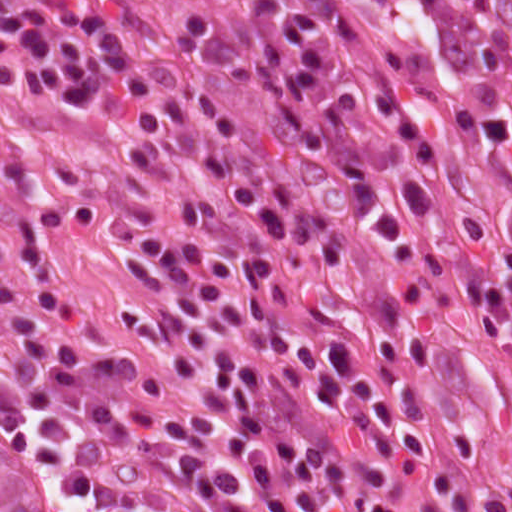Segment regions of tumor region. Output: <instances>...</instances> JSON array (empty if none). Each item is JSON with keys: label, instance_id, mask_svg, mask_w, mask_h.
<instances>
[{"label": "tumor region", "instance_id": "obj_1", "mask_svg": "<svg viewBox=\"0 0 512 512\" xmlns=\"http://www.w3.org/2000/svg\"><path fill=\"white\" fill-rule=\"evenodd\" d=\"M354 66L437 128L475 219L512 253V0H296Z\"/></svg>", "mask_w": 512, "mask_h": 512}]
</instances>
